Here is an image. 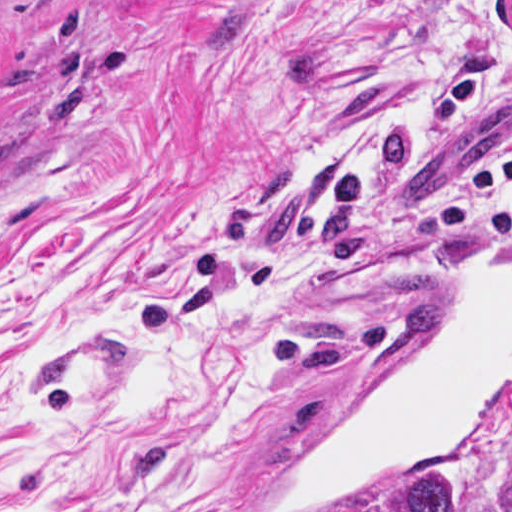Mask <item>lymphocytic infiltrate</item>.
Returning <instances> with one entry per match:
<instances>
[{
  "mask_svg": "<svg viewBox=\"0 0 512 512\" xmlns=\"http://www.w3.org/2000/svg\"><path fill=\"white\" fill-rule=\"evenodd\" d=\"M512 66L477 59L457 67L391 117L348 136L327 165L330 195L392 237L421 246H512V137L467 178H407L404 157L468 103L503 97Z\"/></svg>",
  "mask_w": 512,
  "mask_h": 512,
  "instance_id": "obj_1",
  "label": "lymphocytic infiltrate"
}]
</instances>
